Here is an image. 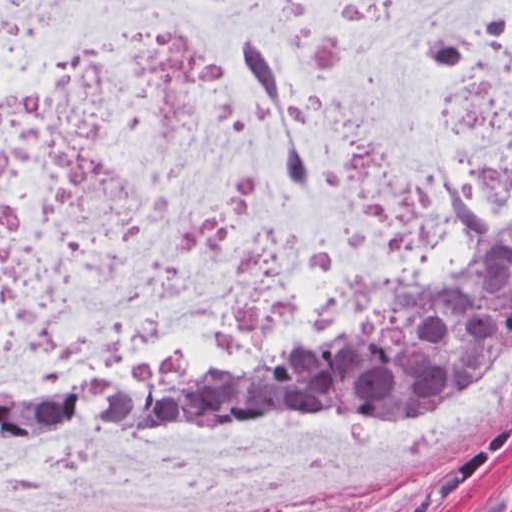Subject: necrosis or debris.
<instances>
[{"label":"necrosis or debris","instance_id":"obj_1","mask_svg":"<svg viewBox=\"0 0 512 512\" xmlns=\"http://www.w3.org/2000/svg\"><path fill=\"white\" fill-rule=\"evenodd\" d=\"M512 246V0H0V394L256 362ZM512 411L0 431V512H305Z\"/></svg>","mask_w":512,"mask_h":512}]
</instances>
